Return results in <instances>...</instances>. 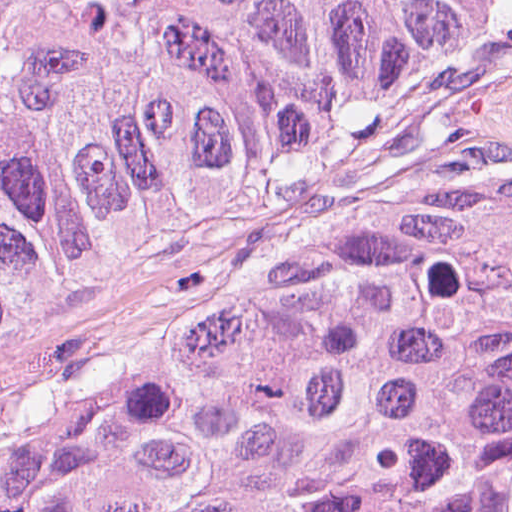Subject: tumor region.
<instances>
[{"label":"tumor region","instance_id":"1","mask_svg":"<svg viewBox=\"0 0 512 512\" xmlns=\"http://www.w3.org/2000/svg\"><path fill=\"white\" fill-rule=\"evenodd\" d=\"M504 0H0V320L184 200L280 182ZM0 512H512V253H415L0 461Z\"/></svg>","mask_w":512,"mask_h":512}]
</instances>
